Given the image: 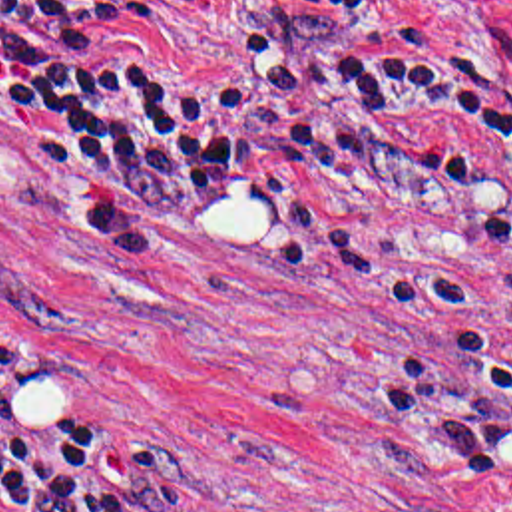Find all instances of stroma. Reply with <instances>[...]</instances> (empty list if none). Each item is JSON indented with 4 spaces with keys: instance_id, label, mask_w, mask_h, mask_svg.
<instances>
[{
    "instance_id": "1",
    "label": "stroma",
    "mask_w": 512,
    "mask_h": 512,
    "mask_svg": "<svg viewBox=\"0 0 512 512\" xmlns=\"http://www.w3.org/2000/svg\"><path fill=\"white\" fill-rule=\"evenodd\" d=\"M410 71L512 111V0H161L139 47L220 79L244 33L390 37ZM414 162H342L200 234H137L0 91V346L15 389L121 427L181 475L177 512H512V146L477 112H388ZM5 377L0 375V391ZM0 512H13L0 491Z\"/></svg>"
}]
</instances>
